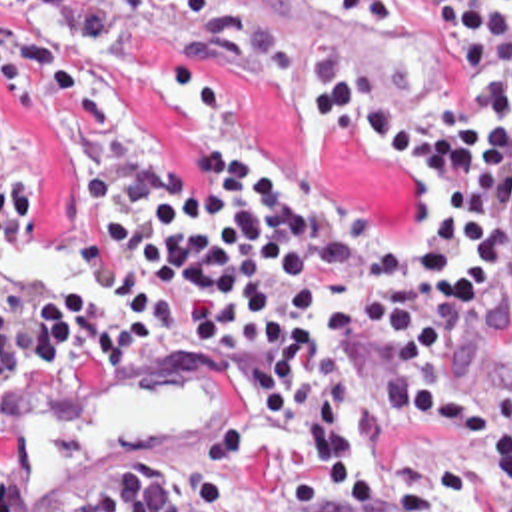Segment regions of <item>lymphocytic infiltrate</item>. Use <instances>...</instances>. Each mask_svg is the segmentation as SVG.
I'll return each mask as SVG.
<instances>
[{
	"mask_svg": "<svg viewBox=\"0 0 512 512\" xmlns=\"http://www.w3.org/2000/svg\"><path fill=\"white\" fill-rule=\"evenodd\" d=\"M14 2L74 46L122 22L120 0ZM416 18L455 58L441 124L330 56L232 52L322 138L406 176L408 222L390 228L338 204L328 162L254 140L210 142L186 194L98 80L0 12V96L82 166L66 254L108 290L98 308L70 284L10 288L0 394L30 354L100 362L214 338L252 364L216 446L142 456L70 512H512V0H416Z\"/></svg>",
	"mask_w": 512,
	"mask_h": 512,
	"instance_id": "obj_1",
	"label": "lymphocytic infiltrate"
}]
</instances>
